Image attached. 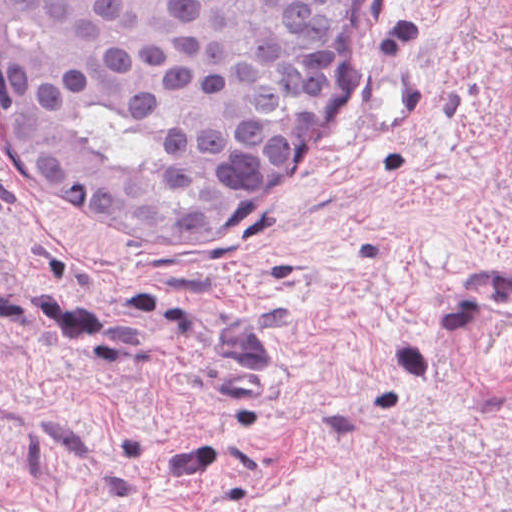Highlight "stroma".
Segmentation results:
<instances>
[{
    "instance_id": "35a3bbf8",
    "label": "stroma",
    "mask_w": 512,
    "mask_h": 512,
    "mask_svg": "<svg viewBox=\"0 0 512 512\" xmlns=\"http://www.w3.org/2000/svg\"><path fill=\"white\" fill-rule=\"evenodd\" d=\"M0 512H512V0H356L194 229H125L0 108Z\"/></svg>"
}]
</instances>
